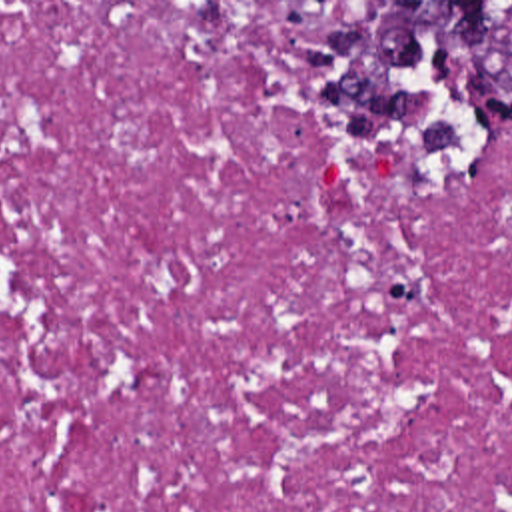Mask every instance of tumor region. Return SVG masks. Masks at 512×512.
<instances>
[{
    "instance_id": "obj_1",
    "label": "tumor region",
    "mask_w": 512,
    "mask_h": 512,
    "mask_svg": "<svg viewBox=\"0 0 512 512\" xmlns=\"http://www.w3.org/2000/svg\"><path fill=\"white\" fill-rule=\"evenodd\" d=\"M304 62L318 114L428 178L472 174L512 126V2H356L304 38Z\"/></svg>"
}]
</instances>
